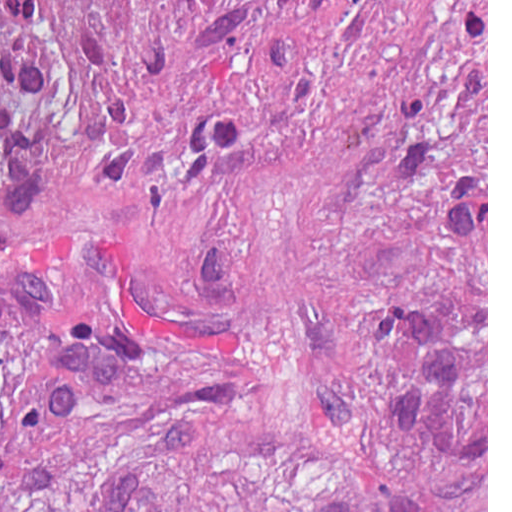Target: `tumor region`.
<instances>
[{"mask_svg":"<svg viewBox=\"0 0 512 512\" xmlns=\"http://www.w3.org/2000/svg\"><path fill=\"white\" fill-rule=\"evenodd\" d=\"M0 512H487V0L0 3Z\"/></svg>","mask_w":512,"mask_h":512,"instance_id":"obj_1","label":"tumor region"}]
</instances>
